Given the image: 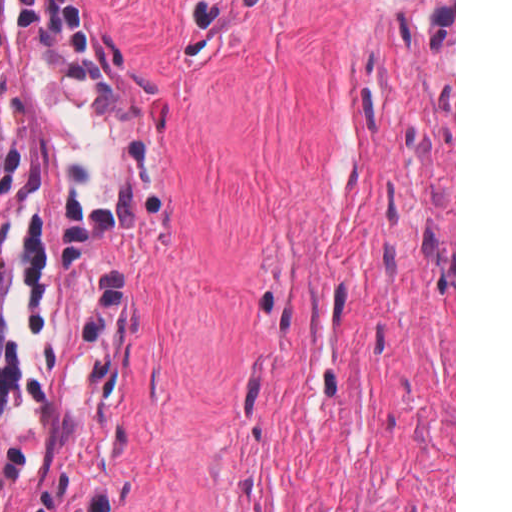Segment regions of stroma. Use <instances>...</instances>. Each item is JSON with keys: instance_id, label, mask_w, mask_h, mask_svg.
I'll return each instance as SVG.
<instances>
[{"instance_id": "35a3bbf8", "label": "stroma", "mask_w": 512, "mask_h": 512, "mask_svg": "<svg viewBox=\"0 0 512 512\" xmlns=\"http://www.w3.org/2000/svg\"><path fill=\"white\" fill-rule=\"evenodd\" d=\"M0 512H224L0 126Z\"/></svg>"}]
</instances>
